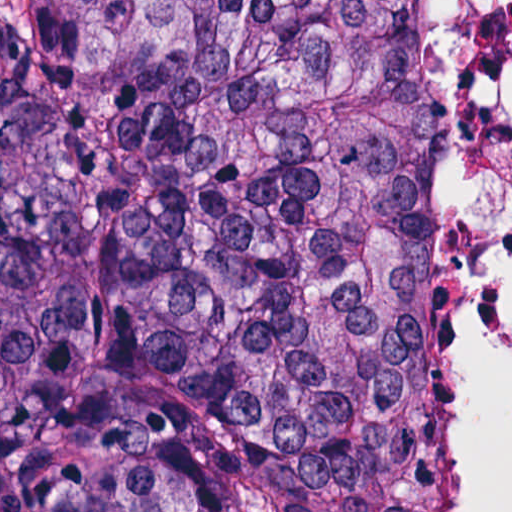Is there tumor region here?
<instances>
[{"label":"tumor region","mask_w":512,"mask_h":512,"mask_svg":"<svg viewBox=\"0 0 512 512\" xmlns=\"http://www.w3.org/2000/svg\"><path fill=\"white\" fill-rule=\"evenodd\" d=\"M0 512H435V0H0Z\"/></svg>","instance_id":"tumor-region-1"}]
</instances>
